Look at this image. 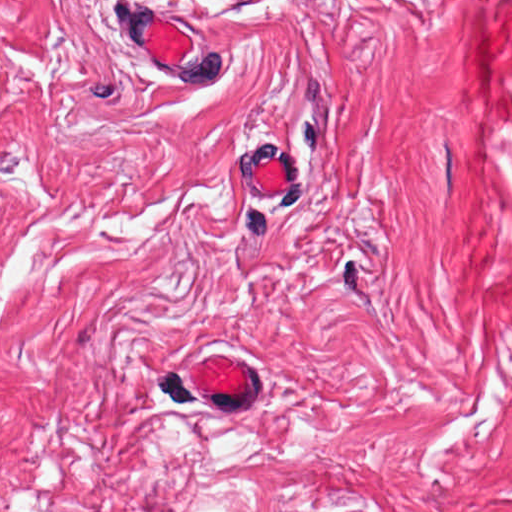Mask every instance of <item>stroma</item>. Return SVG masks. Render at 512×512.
<instances>
[{"label":"stroma","mask_w":512,"mask_h":512,"mask_svg":"<svg viewBox=\"0 0 512 512\" xmlns=\"http://www.w3.org/2000/svg\"><path fill=\"white\" fill-rule=\"evenodd\" d=\"M153 3L226 86L134 62ZM221 346L248 412L187 384ZM0 504L512 512V0H0Z\"/></svg>","instance_id":"1"}]
</instances>
